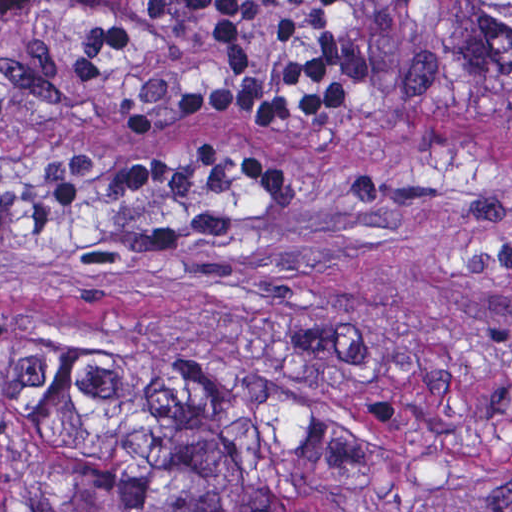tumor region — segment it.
<instances>
[{
  "label": "tumor region",
  "instance_id": "tumor-region-1",
  "mask_svg": "<svg viewBox=\"0 0 512 512\" xmlns=\"http://www.w3.org/2000/svg\"><path fill=\"white\" fill-rule=\"evenodd\" d=\"M386 86L512 128V0H364ZM347 393L232 339L162 334L0 393V512H337Z\"/></svg>",
  "mask_w": 512,
  "mask_h": 512
}]
</instances>
